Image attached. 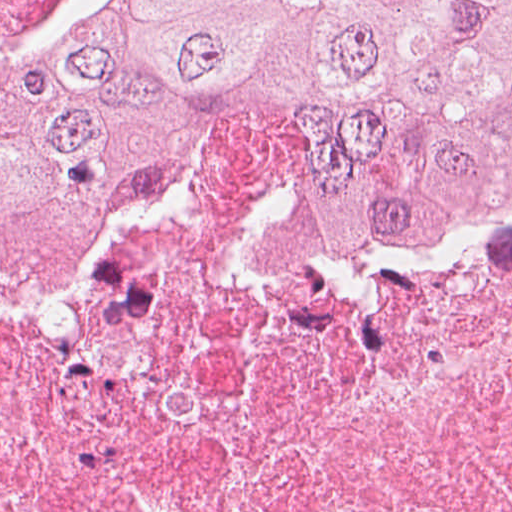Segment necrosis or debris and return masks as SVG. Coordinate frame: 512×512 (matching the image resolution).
<instances>
[{
  "instance_id": "obj_1",
  "label": "necrosis or debris",
  "mask_w": 512,
  "mask_h": 512,
  "mask_svg": "<svg viewBox=\"0 0 512 512\" xmlns=\"http://www.w3.org/2000/svg\"><path fill=\"white\" fill-rule=\"evenodd\" d=\"M0 512H512V159L388 264L268 148L193 147L0 294Z\"/></svg>"
}]
</instances>
